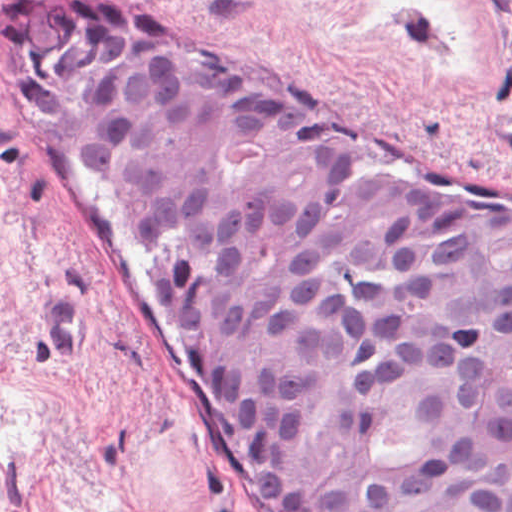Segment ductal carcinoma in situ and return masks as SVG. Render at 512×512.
<instances>
[{
	"mask_svg": "<svg viewBox=\"0 0 512 512\" xmlns=\"http://www.w3.org/2000/svg\"><path fill=\"white\" fill-rule=\"evenodd\" d=\"M274 512H512V192L281 108L147 8L13 0Z\"/></svg>",
	"mask_w": 512,
	"mask_h": 512,
	"instance_id": "obj_1",
	"label": "ductal carcinoma in situ"
}]
</instances>
